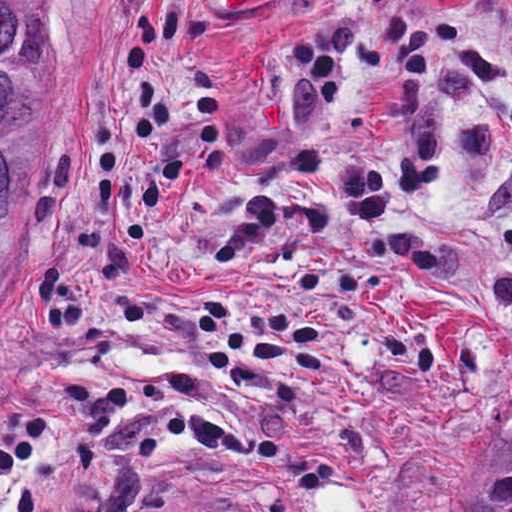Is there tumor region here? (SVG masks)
<instances>
[{"instance_id": "e687c5a6", "label": "tumor region", "mask_w": 512, "mask_h": 512, "mask_svg": "<svg viewBox=\"0 0 512 512\" xmlns=\"http://www.w3.org/2000/svg\"><path fill=\"white\" fill-rule=\"evenodd\" d=\"M47 60L42 0H0V269L36 202L30 139ZM461 512H512V404L476 466Z\"/></svg>"}]
</instances>
